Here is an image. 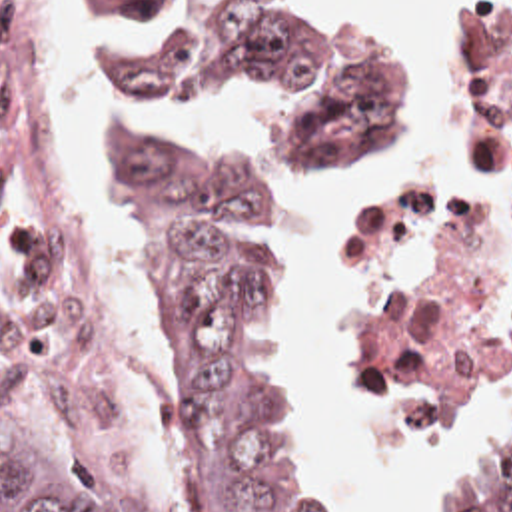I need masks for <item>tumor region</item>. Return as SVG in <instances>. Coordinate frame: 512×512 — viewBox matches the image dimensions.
Returning <instances> with one entry per match:
<instances>
[{"label": "tumor region", "mask_w": 512, "mask_h": 512, "mask_svg": "<svg viewBox=\"0 0 512 512\" xmlns=\"http://www.w3.org/2000/svg\"><path fill=\"white\" fill-rule=\"evenodd\" d=\"M152 0H76L94 20ZM317 34L299 0H249L138 66L144 98L253 92L307 72ZM84 70V58L80 50ZM86 78V74H84ZM397 56L325 122L295 138L291 174L343 160L389 112ZM146 288L168 326L186 393V512H345L317 459L307 379L275 268V196L245 162L192 146L142 160ZM0 512H138L54 439L0 374ZM449 512H512V447L499 449Z\"/></svg>", "instance_id": "1"}]
</instances>
